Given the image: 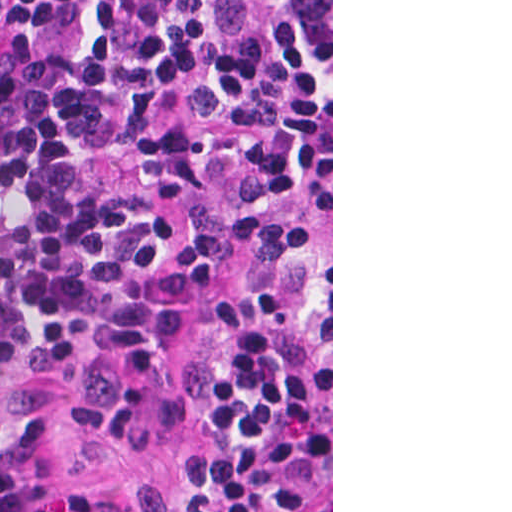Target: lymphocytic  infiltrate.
I'll return each mask as SVG.
<instances>
[{"label":"lymphocytic infiltrate","instance_id":"f902f5d3","mask_svg":"<svg viewBox=\"0 0 512 512\" xmlns=\"http://www.w3.org/2000/svg\"><path fill=\"white\" fill-rule=\"evenodd\" d=\"M329 416L331 0H0V430L200 426L158 512H292Z\"/></svg>","mask_w":512,"mask_h":512}]
</instances>
